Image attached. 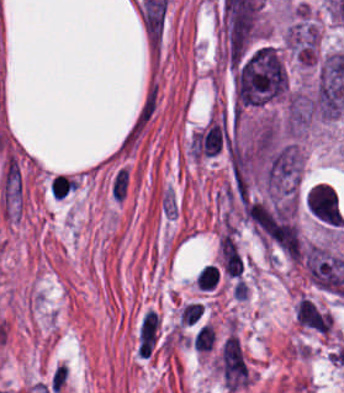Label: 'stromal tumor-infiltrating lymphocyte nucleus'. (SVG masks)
<instances>
[{
    "instance_id": "stromal-tumor-infiltrating-lymphocyte-nucleus-1",
    "label": "stromal tumor-infiltrating lymphocyte nucleus",
    "mask_w": 344,
    "mask_h": 393,
    "mask_svg": "<svg viewBox=\"0 0 344 393\" xmlns=\"http://www.w3.org/2000/svg\"><path fill=\"white\" fill-rule=\"evenodd\" d=\"M219 256L224 273L240 279L243 261L229 228L219 236Z\"/></svg>"
},
{
    "instance_id": "stromal-tumor-infiltrating-lymphocyte-nucleus-2",
    "label": "stromal tumor-infiltrating lymphocyte nucleus",
    "mask_w": 344,
    "mask_h": 393,
    "mask_svg": "<svg viewBox=\"0 0 344 393\" xmlns=\"http://www.w3.org/2000/svg\"><path fill=\"white\" fill-rule=\"evenodd\" d=\"M215 344V330L208 324H204L193 337V348L198 352H211Z\"/></svg>"
},
{
    "instance_id": "stromal-tumor-infiltrating-lymphocyte-nucleus-3",
    "label": "stromal tumor-infiltrating lymphocyte nucleus",
    "mask_w": 344,
    "mask_h": 393,
    "mask_svg": "<svg viewBox=\"0 0 344 393\" xmlns=\"http://www.w3.org/2000/svg\"><path fill=\"white\" fill-rule=\"evenodd\" d=\"M220 273L216 264L207 263L197 274L196 281L200 290H211L218 282Z\"/></svg>"
},
{
    "instance_id": "stromal-tumor-infiltrating-lymphocyte-nucleus-4",
    "label": "stromal tumor-infiltrating lymphocyte nucleus",
    "mask_w": 344,
    "mask_h": 393,
    "mask_svg": "<svg viewBox=\"0 0 344 393\" xmlns=\"http://www.w3.org/2000/svg\"><path fill=\"white\" fill-rule=\"evenodd\" d=\"M201 302L191 301L183 306L179 316L182 324H194L203 314Z\"/></svg>"
}]
</instances>
